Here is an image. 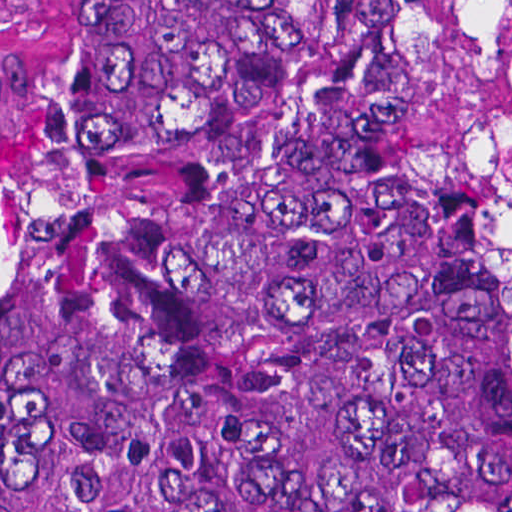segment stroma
<instances>
[{
  "label": "stroma",
  "instance_id": "stroma-1",
  "mask_svg": "<svg viewBox=\"0 0 512 512\" xmlns=\"http://www.w3.org/2000/svg\"><path fill=\"white\" fill-rule=\"evenodd\" d=\"M385 24L443 0H373ZM0 157L73 190V37L62 0H0Z\"/></svg>",
  "mask_w": 512,
  "mask_h": 512
}]
</instances>
